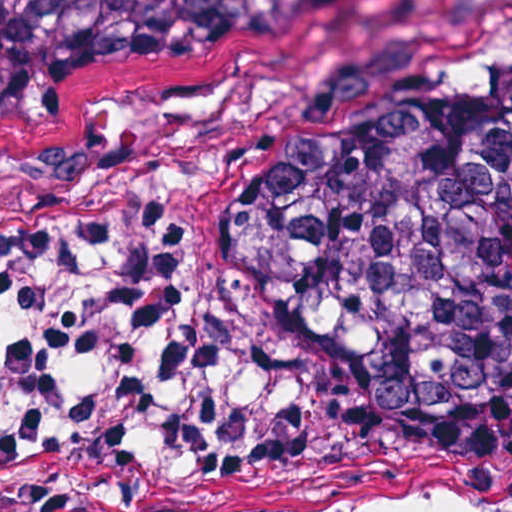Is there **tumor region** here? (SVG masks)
Listing matches in <instances>:
<instances>
[{"label":"tumor region","instance_id":"1","mask_svg":"<svg viewBox=\"0 0 512 512\" xmlns=\"http://www.w3.org/2000/svg\"><path fill=\"white\" fill-rule=\"evenodd\" d=\"M378 0H0V124L93 84L326 64ZM180 278L217 337L397 419L512 431V0L398 96L317 91Z\"/></svg>","mask_w":512,"mask_h":512}]
</instances>
